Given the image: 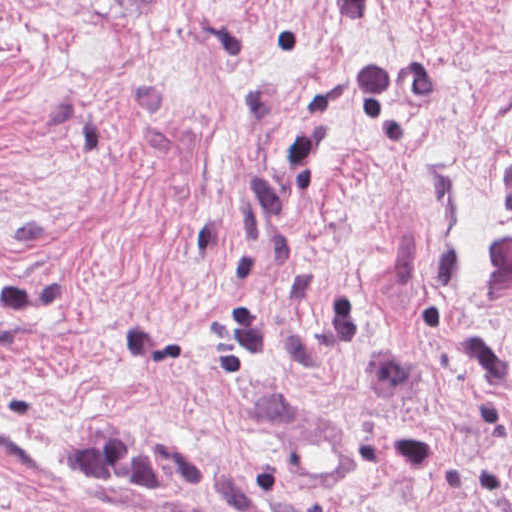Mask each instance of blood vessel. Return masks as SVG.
<instances>
[{"instance_id": "blood-vessel-1", "label": "blood vessel", "mask_w": 512, "mask_h": 512, "mask_svg": "<svg viewBox=\"0 0 512 512\" xmlns=\"http://www.w3.org/2000/svg\"><path fill=\"white\" fill-rule=\"evenodd\" d=\"M337 426L342 428L335 421L301 420L299 469L306 492L331 494L349 474V442Z\"/></svg>"}]
</instances>
